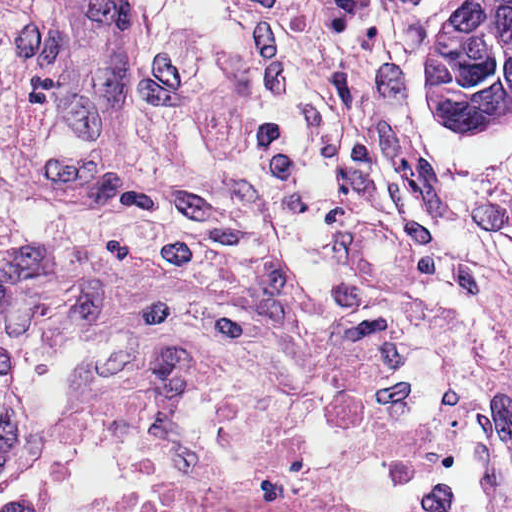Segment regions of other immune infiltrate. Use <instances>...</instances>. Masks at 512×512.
I'll use <instances>...</instances> for the list:
<instances>
[{
  "label": "other immune infiltrate",
  "instance_id": "bc1004c8",
  "mask_svg": "<svg viewBox=\"0 0 512 512\" xmlns=\"http://www.w3.org/2000/svg\"><path fill=\"white\" fill-rule=\"evenodd\" d=\"M223 136L203 0H0V214L194 203Z\"/></svg>",
  "mask_w": 512,
  "mask_h": 512
}]
</instances>
